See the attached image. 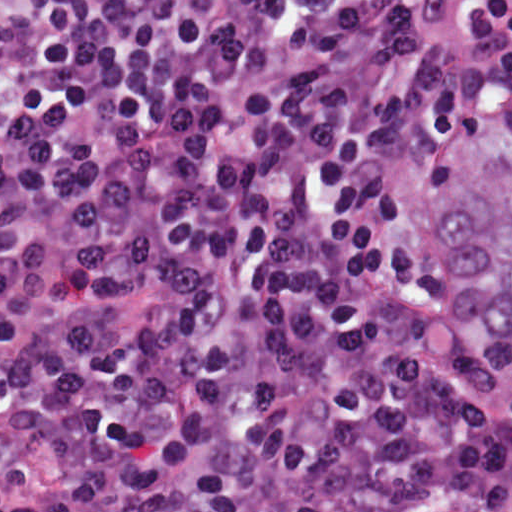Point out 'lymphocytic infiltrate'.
Listing matches in <instances>:
<instances>
[{"label": "lymphocytic infiltrate", "mask_w": 512, "mask_h": 512, "mask_svg": "<svg viewBox=\"0 0 512 512\" xmlns=\"http://www.w3.org/2000/svg\"><path fill=\"white\" fill-rule=\"evenodd\" d=\"M511 127L512 0H0L15 512H512L439 298Z\"/></svg>", "instance_id": "lymphocytic-infiltrate-1"}]
</instances>
